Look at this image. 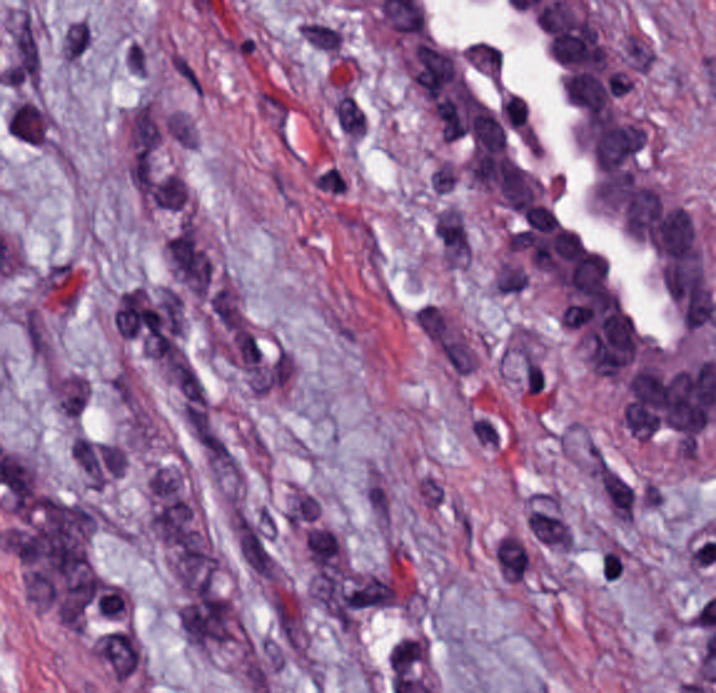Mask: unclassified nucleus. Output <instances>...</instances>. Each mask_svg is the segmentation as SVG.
<instances>
[{"label":"unclassified nucleus","instance_id":"1","mask_svg":"<svg viewBox=\"0 0 716 693\" xmlns=\"http://www.w3.org/2000/svg\"><path fill=\"white\" fill-rule=\"evenodd\" d=\"M650 252H716V206H650Z\"/></svg>","mask_w":716,"mask_h":693},{"label":"unclassified nucleus","instance_id":"2","mask_svg":"<svg viewBox=\"0 0 716 693\" xmlns=\"http://www.w3.org/2000/svg\"><path fill=\"white\" fill-rule=\"evenodd\" d=\"M585 162H651V121H585Z\"/></svg>","mask_w":716,"mask_h":693},{"label":"unclassified nucleus","instance_id":"3","mask_svg":"<svg viewBox=\"0 0 716 693\" xmlns=\"http://www.w3.org/2000/svg\"><path fill=\"white\" fill-rule=\"evenodd\" d=\"M588 217H634V166H588Z\"/></svg>","mask_w":716,"mask_h":693},{"label":"unclassified nucleus","instance_id":"4","mask_svg":"<svg viewBox=\"0 0 716 693\" xmlns=\"http://www.w3.org/2000/svg\"><path fill=\"white\" fill-rule=\"evenodd\" d=\"M618 237H668V191H618Z\"/></svg>","mask_w":716,"mask_h":693},{"label":"unclassified nucleus","instance_id":"5","mask_svg":"<svg viewBox=\"0 0 716 693\" xmlns=\"http://www.w3.org/2000/svg\"><path fill=\"white\" fill-rule=\"evenodd\" d=\"M568 292H619V251H568Z\"/></svg>","mask_w":716,"mask_h":693},{"label":"unclassified nucleus","instance_id":"6","mask_svg":"<svg viewBox=\"0 0 716 693\" xmlns=\"http://www.w3.org/2000/svg\"><path fill=\"white\" fill-rule=\"evenodd\" d=\"M575 379H621V338H575Z\"/></svg>","mask_w":716,"mask_h":693},{"label":"unclassified nucleus","instance_id":"7","mask_svg":"<svg viewBox=\"0 0 716 693\" xmlns=\"http://www.w3.org/2000/svg\"><path fill=\"white\" fill-rule=\"evenodd\" d=\"M418 85H454V39H418Z\"/></svg>","mask_w":716,"mask_h":693},{"label":"unclassified nucleus","instance_id":"8","mask_svg":"<svg viewBox=\"0 0 716 693\" xmlns=\"http://www.w3.org/2000/svg\"><path fill=\"white\" fill-rule=\"evenodd\" d=\"M465 160H501V114H465Z\"/></svg>","mask_w":716,"mask_h":693},{"label":"unclassified nucleus","instance_id":"9","mask_svg":"<svg viewBox=\"0 0 716 693\" xmlns=\"http://www.w3.org/2000/svg\"><path fill=\"white\" fill-rule=\"evenodd\" d=\"M623 444H663V403H623Z\"/></svg>","mask_w":716,"mask_h":693},{"label":"unclassified nucleus","instance_id":"10","mask_svg":"<svg viewBox=\"0 0 716 693\" xmlns=\"http://www.w3.org/2000/svg\"><path fill=\"white\" fill-rule=\"evenodd\" d=\"M558 102H609V71H558Z\"/></svg>","mask_w":716,"mask_h":693},{"label":"unclassified nucleus","instance_id":"11","mask_svg":"<svg viewBox=\"0 0 716 693\" xmlns=\"http://www.w3.org/2000/svg\"><path fill=\"white\" fill-rule=\"evenodd\" d=\"M433 145H464V94H433Z\"/></svg>","mask_w":716,"mask_h":693},{"label":"unclassified nucleus","instance_id":"12","mask_svg":"<svg viewBox=\"0 0 716 693\" xmlns=\"http://www.w3.org/2000/svg\"><path fill=\"white\" fill-rule=\"evenodd\" d=\"M503 205H534V159H503Z\"/></svg>","mask_w":716,"mask_h":693},{"label":"unclassified nucleus","instance_id":"13","mask_svg":"<svg viewBox=\"0 0 716 693\" xmlns=\"http://www.w3.org/2000/svg\"><path fill=\"white\" fill-rule=\"evenodd\" d=\"M553 267H584V226H553Z\"/></svg>","mask_w":716,"mask_h":693},{"label":"unclassified nucleus","instance_id":"14","mask_svg":"<svg viewBox=\"0 0 716 693\" xmlns=\"http://www.w3.org/2000/svg\"><path fill=\"white\" fill-rule=\"evenodd\" d=\"M628 404H663V368H628Z\"/></svg>","mask_w":716,"mask_h":693},{"label":"unclassified nucleus","instance_id":"15","mask_svg":"<svg viewBox=\"0 0 716 693\" xmlns=\"http://www.w3.org/2000/svg\"><path fill=\"white\" fill-rule=\"evenodd\" d=\"M605 344H641V309H605Z\"/></svg>","mask_w":716,"mask_h":693},{"label":"unclassified nucleus","instance_id":"16","mask_svg":"<svg viewBox=\"0 0 716 693\" xmlns=\"http://www.w3.org/2000/svg\"><path fill=\"white\" fill-rule=\"evenodd\" d=\"M498 297H529V261H498Z\"/></svg>","mask_w":716,"mask_h":693},{"label":"unclassified nucleus","instance_id":"17","mask_svg":"<svg viewBox=\"0 0 716 693\" xmlns=\"http://www.w3.org/2000/svg\"><path fill=\"white\" fill-rule=\"evenodd\" d=\"M560 325H596V294H560Z\"/></svg>","mask_w":716,"mask_h":693},{"label":"unclassified nucleus","instance_id":"18","mask_svg":"<svg viewBox=\"0 0 716 693\" xmlns=\"http://www.w3.org/2000/svg\"><path fill=\"white\" fill-rule=\"evenodd\" d=\"M473 187H499V151H473Z\"/></svg>","mask_w":716,"mask_h":693}]
</instances>
